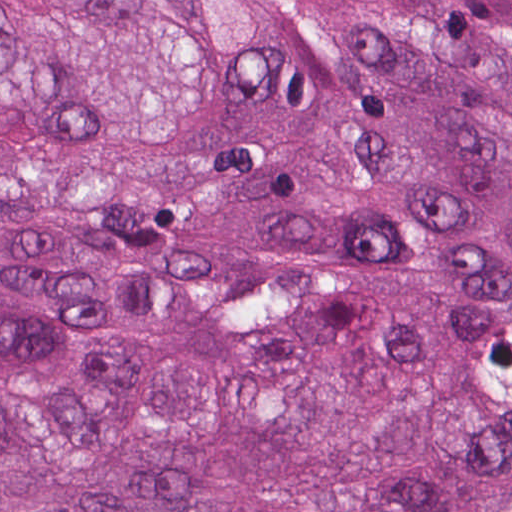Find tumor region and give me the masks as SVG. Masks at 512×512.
Returning <instances> with one entry per match:
<instances>
[{
	"mask_svg": "<svg viewBox=\"0 0 512 512\" xmlns=\"http://www.w3.org/2000/svg\"><path fill=\"white\" fill-rule=\"evenodd\" d=\"M0 512H512V0H0Z\"/></svg>",
	"mask_w": 512,
	"mask_h": 512,
	"instance_id": "tumor-region-1",
	"label": "tumor region"
}]
</instances>
